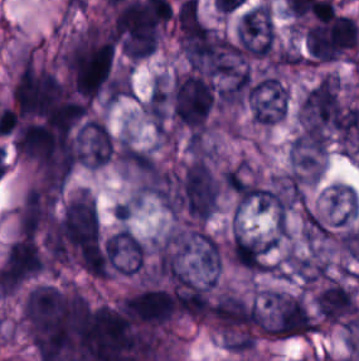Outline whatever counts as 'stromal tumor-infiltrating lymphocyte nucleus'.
Wrapping results in <instances>:
<instances>
[{"label":"stromal tumor-infiltrating lymphocyte nucleus","mask_w":359,"mask_h":361,"mask_svg":"<svg viewBox=\"0 0 359 361\" xmlns=\"http://www.w3.org/2000/svg\"><path fill=\"white\" fill-rule=\"evenodd\" d=\"M41 264L36 244L30 237L19 236L9 243L0 270L3 274L20 281L37 274Z\"/></svg>","instance_id":"bc302bb0"}]
</instances>
